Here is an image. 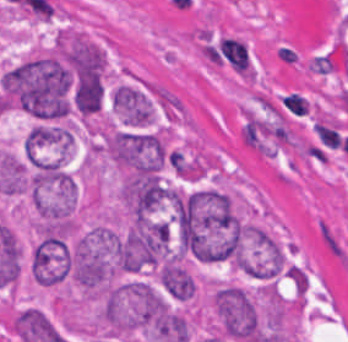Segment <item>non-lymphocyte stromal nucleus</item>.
<instances>
[{
  "instance_id": "1",
  "label": "non-lymphocyte stromal nucleus",
  "mask_w": 348,
  "mask_h": 342,
  "mask_svg": "<svg viewBox=\"0 0 348 342\" xmlns=\"http://www.w3.org/2000/svg\"><path fill=\"white\" fill-rule=\"evenodd\" d=\"M317 236L324 250L337 262L348 263V247L343 238L323 219L317 221Z\"/></svg>"
}]
</instances>
